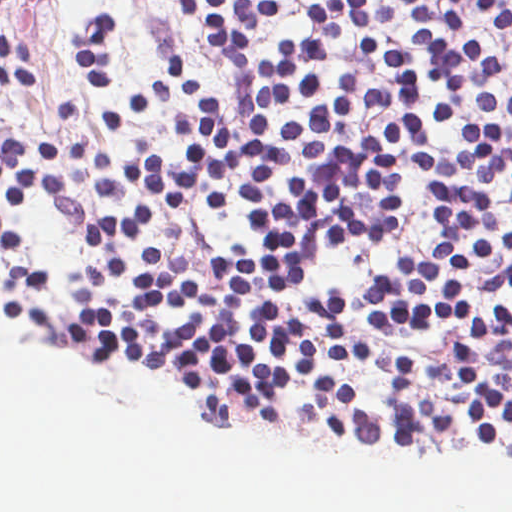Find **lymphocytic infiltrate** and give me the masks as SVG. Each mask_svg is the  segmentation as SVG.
<instances>
[{"mask_svg":"<svg viewBox=\"0 0 512 512\" xmlns=\"http://www.w3.org/2000/svg\"><path fill=\"white\" fill-rule=\"evenodd\" d=\"M13 0H0V8ZM282 0H185L237 105L217 104L192 64L166 79L192 108L172 122L188 144L171 161L147 152L116 162L100 148L88 190L170 216L201 206L246 212L252 243L316 264L334 248L351 256L399 236L412 157L427 180L438 223L434 241L387 258L368 281L512 327V304L478 310L468 277L487 268L512 294V152L504 129L461 122L460 151L437 156L429 127L457 122L464 90L483 111L512 116V0H312L308 33L275 55L252 51ZM116 16L93 12L76 42L92 87L110 88ZM0 81H40L28 43L0 35ZM23 147L52 163L58 144L0 132V161L69 184L25 162Z\"/></svg>","mask_w":512,"mask_h":512,"instance_id":"obj_1","label":"lymphocytic infiltrate"}]
</instances>
